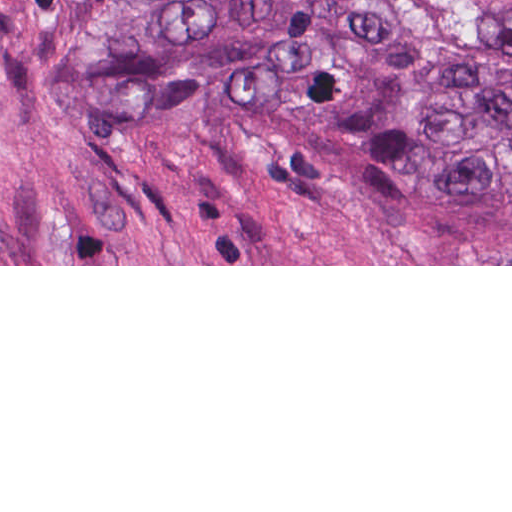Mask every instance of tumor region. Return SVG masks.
<instances>
[{
    "label": "tumor region",
    "instance_id": "obj_1",
    "mask_svg": "<svg viewBox=\"0 0 512 512\" xmlns=\"http://www.w3.org/2000/svg\"><path fill=\"white\" fill-rule=\"evenodd\" d=\"M512 50V0H406ZM50 86L80 110L158 119L239 89L395 191L512 231V63L377 0H92Z\"/></svg>",
    "mask_w": 512,
    "mask_h": 512
}]
</instances>
